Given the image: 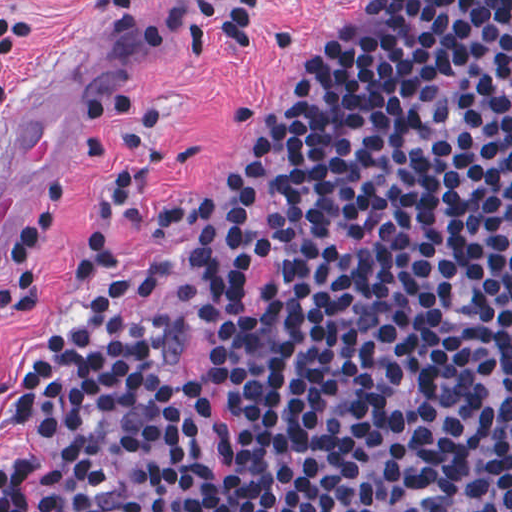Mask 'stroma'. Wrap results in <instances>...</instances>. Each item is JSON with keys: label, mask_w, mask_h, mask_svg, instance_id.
I'll return each instance as SVG.
<instances>
[{"label": "stroma", "mask_w": 512, "mask_h": 512, "mask_svg": "<svg viewBox=\"0 0 512 512\" xmlns=\"http://www.w3.org/2000/svg\"><path fill=\"white\" fill-rule=\"evenodd\" d=\"M384 0H261L258 33L246 45L211 43L200 55L189 40L154 42L140 26L185 15L178 0H151L135 16H111L85 0H0V13L24 16L22 50L10 76L12 108L0 114V133L72 59L110 17L144 53L137 86L105 116L93 121L69 156L77 196L71 224L47 242L50 286L35 323L0 329V375L73 319L74 297L64 278L81 226L92 223L116 266L158 279L159 292L129 303L154 324L166 325L174 344L170 374L183 398L185 420L208 460L220 462L223 434L200 397V381L216 357L202 316L219 306L250 313L265 306L275 281L270 260L252 261L249 283L238 292L210 291L185 243L168 235H138L107 206L105 185L115 154L138 110L158 116L151 148L138 166L139 186L190 191L207 185L233 161L248 136L230 126L236 107L260 96L301 91L326 62L357 36ZM7 237L0 242V277L7 271ZM30 443L0 420V468L32 456Z\"/></svg>", "instance_id": "obj_1"}]
</instances>
